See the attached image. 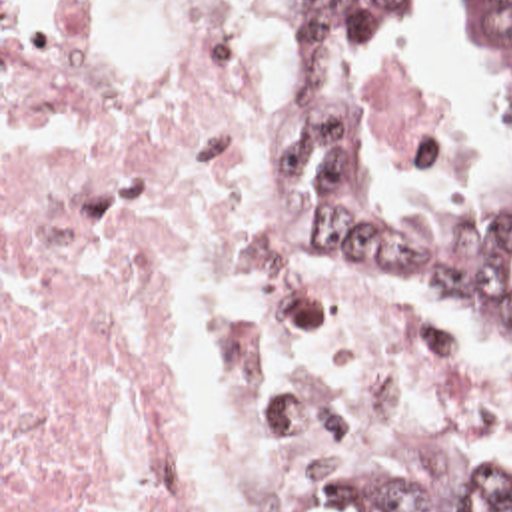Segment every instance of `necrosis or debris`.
<instances>
[{
    "mask_svg": "<svg viewBox=\"0 0 512 512\" xmlns=\"http://www.w3.org/2000/svg\"><path fill=\"white\" fill-rule=\"evenodd\" d=\"M298 74L294 0L2 6V512H300L367 442L512 456L491 380L317 264L262 142ZM361 110L411 198L489 188L463 40Z\"/></svg>",
    "mask_w": 512,
    "mask_h": 512,
    "instance_id": "necrosis-or-debris-1",
    "label": "necrosis or debris"
}]
</instances>
